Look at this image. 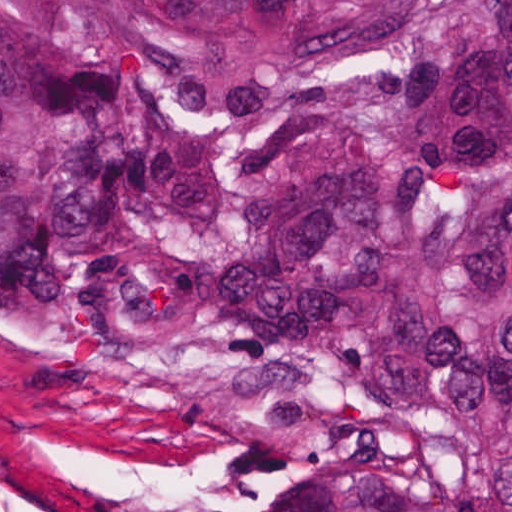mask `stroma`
<instances>
[{
  "label": "stroma",
  "mask_w": 512,
  "mask_h": 512,
  "mask_svg": "<svg viewBox=\"0 0 512 512\" xmlns=\"http://www.w3.org/2000/svg\"><path fill=\"white\" fill-rule=\"evenodd\" d=\"M257 440L148 404L0 323V512H224Z\"/></svg>",
  "instance_id": "stroma-1"
}]
</instances>
